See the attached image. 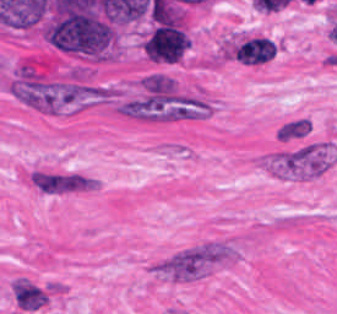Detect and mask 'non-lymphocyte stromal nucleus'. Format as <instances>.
<instances>
[{
  "instance_id": "non-lymphocyte-stromal-nucleus-1",
  "label": "non-lymphocyte stromal nucleus",
  "mask_w": 337,
  "mask_h": 314,
  "mask_svg": "<svg viewBox=\"0 0 337 314\" xmlns=\"http://www.w3.org/2000/svg\"><path fill=\"white\" fill-rule=\"evenodd\" d=\"M337 158L332 143L301 142L262 154L257 165L285 180H311L328 170Z\"/></svg>"
},
{
  "instance_id": "non-lymphocyte-stromal-nucleus-2",
  "label": "non-lymphocyte stromal nucleus",
  "mask_w": 337,
  "mask_h": 314,
  "mask_svg": "<svg viewBox=\"0 0 337 314\" xmlns=\"http://www.w3.org/2000/svg\"><path fill=\"white\" fill-rule=\"evenodd\" d=\"M31 188L42 195H68L100 185V180L74 170L32 169L26 179Z\"/></svg>"
},
{
  "instance_id": "non-lymphocyte-stromal-nucleus-3",
  "label": "non-lymphocyte stromal nucleus",
  "mask_w": 337,
  "mask_h": 314,
  "mask_svg": "<svg viewBox=\"0 0 337 314\" xmlns=\"http://www.w3.org/2000/svg\"><path fill=\"white\" fill-rule=\"evenodd\" d=\"M274 44L264 36L241 42L234 50V58L246 64H259L274 56Z\"/></svg>"
},
{
  "instance_id": "non-lymphocyte-stromal-nucleus-4",
  "label": "non-lymphocyte stromal nucleus",
  "mask_w": 337,
  "mask_h": 314,
  "mask_svg": "<svg viewBox=\"0 0 337 314\" xmlns=\"http://www.w3.org/2000/svg\"><path fill=\"white\" fill-rule=\"evenodd\" d=\"M313 128L310 116L297 115L284 120L277 131L275 139L279 142H291L309 135Z\"/></svg>"
}]
</instances>
